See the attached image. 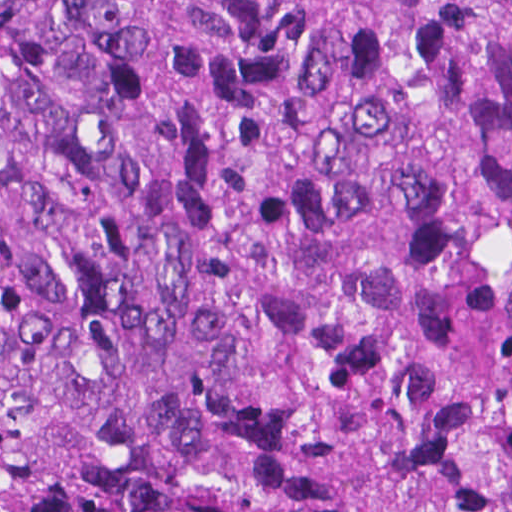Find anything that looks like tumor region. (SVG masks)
<instances>
[{"mask_svg": "<svg viewBox=\"0 0 512 512\" xmlns=\"http://www.w3.org/2000/svg\"><path fill=\"white\" fill-rule=\"evenodd\" d=\"M0 512H512V0H0Z\"/></svg>", "mask_w": 512, "mask_h": 512, "instance_id": "e687c5a6", "label": "tumor region"}]
</instances>
